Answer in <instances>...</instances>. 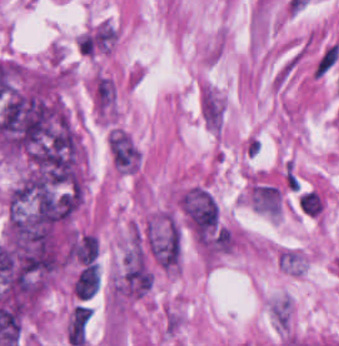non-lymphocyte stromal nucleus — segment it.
I'll use <instances>...</instances> for the list:
<instances>
[{
    "label": "non-lymphocyte stromal nucleus",
    "mask_w": 339,
    "mask_h": 346,
    "mask_svg": "<svg viewBox=\"0 0 339 346\" xmlns=\"http://www.w3.org/2000/svg\"><path fill=\"white\" fill-rule=\"evenodd\" d=\"M339 58V41L325 44L319 51L312 67L311 76L323 78Z\"/></svg>",
    "instance_id": "3746e769"
},
{
    "label": "non-lymphocyte stromal nucleus",
    "mask_w": 339,
    "mask_h": 346,
    "mask_svg": "<svg viewBox=\"0 0 339 346\" xmlns=\"http://www.w3.org/2000/svg\"><path fill=\"white\" fill-rule=\"evenodd\" d=\"M270 313L276 322L285 328L290 323V302L289 299H275L270 303Z\"/></svg>",
    "instance_id": "7c5642bf"
},
{
    "label": "non-lymphocyte stromal nucleus",
    "mask_w": 339,
    "mask_h": 346,
    "mask_svg": "<svg viewBox=\"0 0 339 346\" xmlns=\"http://www.w3.org/2000/svg\"><path fill=\"white\" fill-rule=\"evenodd\" d=\"M202 118L211 129L221 128L223 122L222 98L213 86L205 85L200 96Z\"/></svg>",
    "instance_id": "a72fc3eb"
},
{
    "label": "non-lymphocyte stromal nucleus",
    "mask_w": 339,
    "mask_h": 346,
    "mask_svg": "<svg viewBox=\"0 0 339 346\" xmlns=\"http://www.w3.org/2000/svg\"><path fill=\"white\" fill-rule=\"evenodd\" d=\"M277 258L282 270L290 274H300L302 270L300 253L292 248L277 252Z\"/></svg>",
    "instance_id": "81446118"
},
{
    "label": "non-lymphocyte stromal nucleus",
    "mask_w": 339,
    "mask_h": 346,
    "mask_svg": "<svg viewBox=\"0 0 339 346\" xmlns=\"http://www.w3.org/2000/svg\"><path fill=\"white\" fill-rule=\"evenodd\" d=\"M152 285V271L138 238L132 235L111 282L120 298L143 297Z\"/></svg>",
    "instance_id": "dd21d789"
},
{
    "label": "non-lymphocyte stromal nucleus",
    "mask_w": 339,
    "mask_h": 346,
    "mask_svg": "<svg viewBox=\"0 0 339 346\" xmlns=\"http://www.w3.org/2000/svg\"><path fill=\"white\" fill-rule=\"evenodd\" d=\"M250 195L266 214L282 201L268 183L257 180Z\"/></svg>",
    "instance_id": "fc2b8d12"
}]
</instances>
